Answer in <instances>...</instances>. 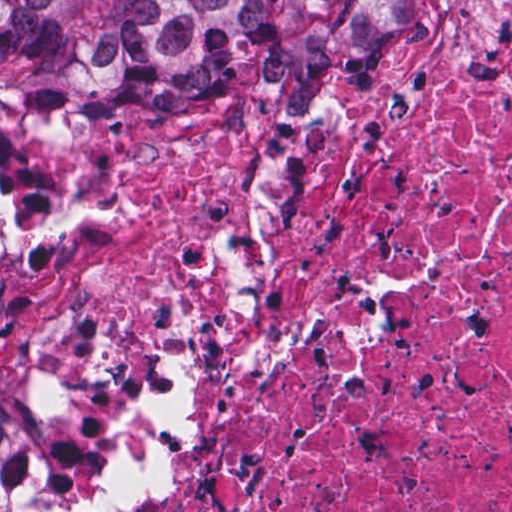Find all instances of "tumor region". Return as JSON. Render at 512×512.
<instances>
[{"label":"tumor region","mask_w":512,"mask_h":512,"mask_svg":"<svg viewBox=\"0 0 512 512\" xmlns=\"http://www.w3.org/2000/svg\"><path fill=\"white\" fill-rule=\"evenodd\" d=\"M360 1H0V105L176 102L234 64L335 55ZM23 397L0 395V466Z\"/></svg>","instance_id":"1"}]
</instances>
